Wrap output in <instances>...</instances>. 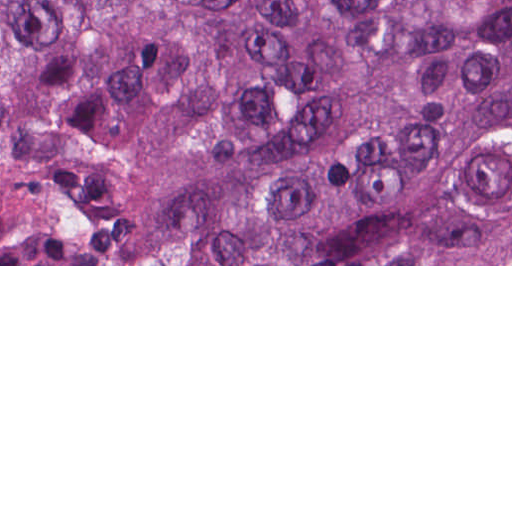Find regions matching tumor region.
<instances>
[{
	"label": "tumor region",
	"instance_id": "e687c5a6",
	"mask_svg": "<svg viewBox=\"0 0 512 512\" xmlns=\"http://www.w3.org/2000/svg\"><path fill=\"white\" fill-rule=\"evenodd\" d=\"M0 264H512V0H0Z\"/></svg>",
	"mask_w": 512,
	"mask_h": 512
}]
</instances>
